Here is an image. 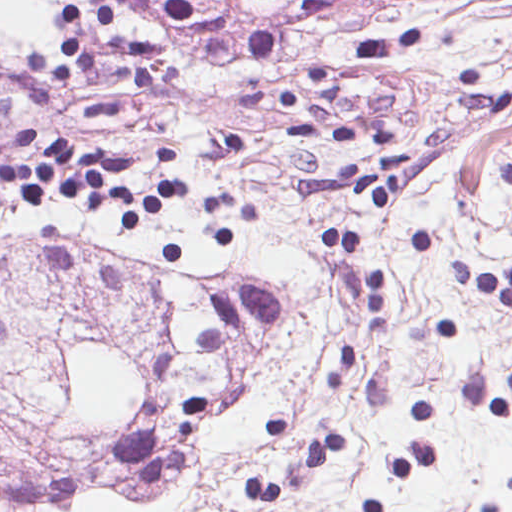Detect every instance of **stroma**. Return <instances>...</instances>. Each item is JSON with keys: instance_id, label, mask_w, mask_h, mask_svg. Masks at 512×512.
<instances>
[{"instance_id": "stroma-1", "label": "stroma", "mask_w": 512, "mask_h": 512, "mask_svg": "<svg viewBox=\"0 0 512 512\" xmlns=\"http://www.w3.org/2000/svg\"><path fill=\"white\" fill-rule=\"evenodd\" d=\"M303 3L214 33L86 0L58 41H0V138L131 158L138 193L176 152L140 234L0 181V494L65 510L197 467L174 512H512V321L451 274L512 265V0ZM320 65L327 128L406 158L404 208L304 191L386 153L288 129ZM325 228L388 278L381 325Z\"/></svg>"}]
</instances>
